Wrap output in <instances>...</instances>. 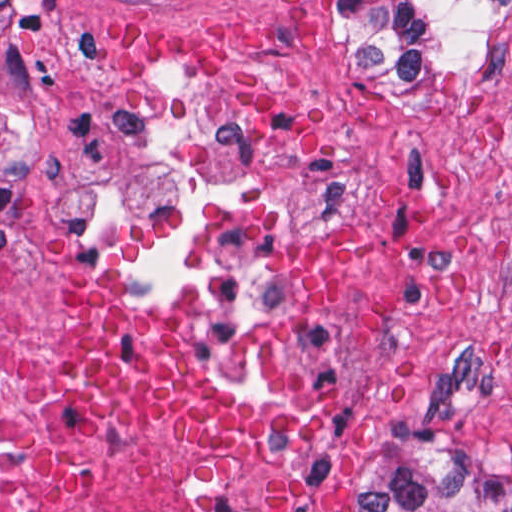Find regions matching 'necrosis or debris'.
Listing matches in <instances>:
<instances>
[{"mask_svg":"<svg viewBox=\"0 0 512 512\" xmlns=\"http://www.w3.org/2000/svg\"><path fill=\"white\" fill-rule=\"evenodd\" d=\"M263 507L264 477L249 462L166 459L79 420L61 395L29 269L0 244V512Z\"/></svg>","mask_w":512,"mask_h":512,"instance_id":"obj_1","label":"necrosis or debris"}]
</instances>
